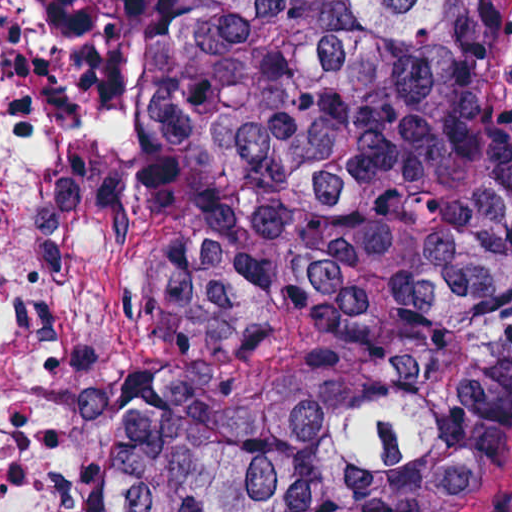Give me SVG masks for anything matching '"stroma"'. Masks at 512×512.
I'll list each match as a JSON object with an SVG mask.
<instances>
[{
  "label": "stroma",
  "mask_w": 512,
  "mask_h": 512,
  "mask_svg": "<svg viewBox=\"0 0 512 512\" xmlns=\"http://www.w3.org/2000/svg\"><path fill=\"white\" fill-rule=\"evenodd\" d=\"M37 13L54 41V23L44 0ZM45 255L81 264L97 295L130 314L140 336L146 365L111 378V460L98 512H128L133 493L149 383V304L116 230L76 153L54 169ZM447 512H512V427L489 474Z\"/></svg>",
  "instance_id": "obj_1"
}]
</instances>
